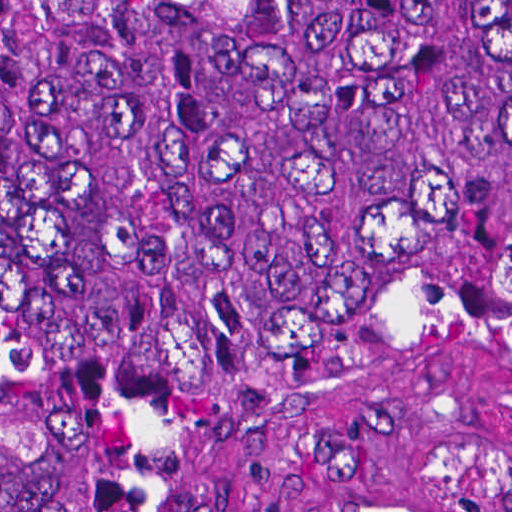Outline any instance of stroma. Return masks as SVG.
<instances>
[{"mask_svg":"<svg viewBox=\"0 0 512 512\" xmlns=\"http://www.w3.org/2000/svg\"><path fill=\"white\" fill-rule=\"evenodd\" d=\"M192 512H512V401L321 393L215 439Z\"/></svg>","mask_w":512,"mask_h":512,"instance_id":"1","label":"stroma"}]
</instances>
